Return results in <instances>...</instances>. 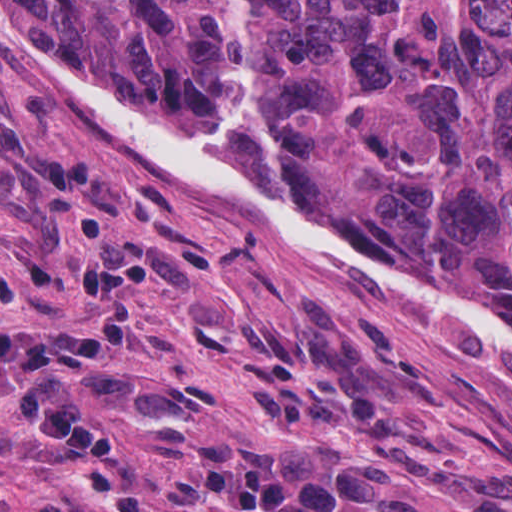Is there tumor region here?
I'll return each instance as SVG.
<instances>
[{
	"mask_svg": "<svg viewBox=\"0 0 512 512\" xmlns=\"http://www.w3.org/2000/svg\"><path fill=\"white\" fill-rule=\"evenodd\" d=\"M140 111L214 121L230 0H19ZM251 93L308 176L397 256L512 315V0H252Z\"/></svg>",
	"mask_w": 512,
	"mask_h": 512,
	"instance_id": "e687c5a6",
	"label": "tumor region"
}]
</instances>
